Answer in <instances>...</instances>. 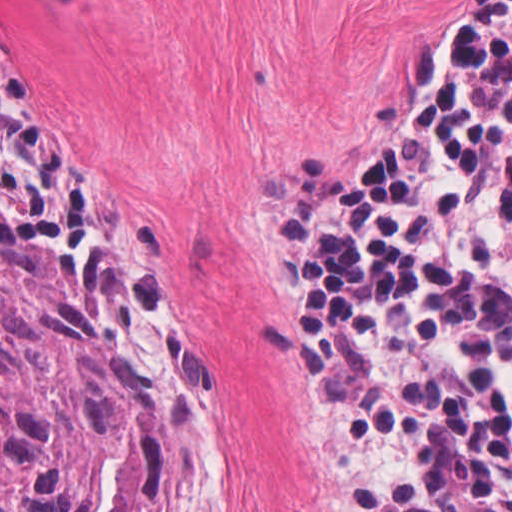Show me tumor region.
Returning <instances> with one entry per match:
<instances>
[{
    "instance_id": "tumor-region-1",
    "label": "tumor region",
    "mask_w": 512,
    "mask_h": 512,
    "mask_svg": "<svg viewBox=\"0 0 512 512\" xmlns=\"http://www.w3.org/2000/svg\"><path fill=\"white\" fill-rule=\"evenodd\" d=\"M0 512H198L141 371L1 224Z\"/></svg>"
}]
</instances>
